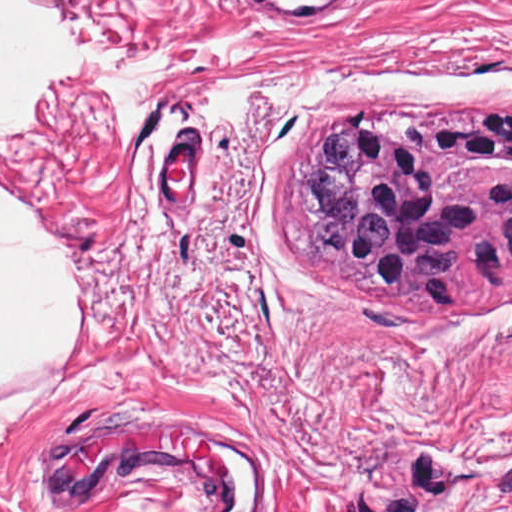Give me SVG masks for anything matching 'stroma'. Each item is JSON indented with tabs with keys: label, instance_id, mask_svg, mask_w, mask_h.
<instances>
[{
	"label": "stroma",
	"instance_id": "stroma-1",
	"mask_svg": "<svg viewBox=\"0 0 512 512\" xmlns=\"http://www.w3.org/2000/svg\"><path fill=\"white\" fill-rule=\"evenodd\" d=\"M80 260L0 512H512V302Z\"/></svg>",
	"mask_w": 512,
	"mask_h": 512
}]
</instances>
